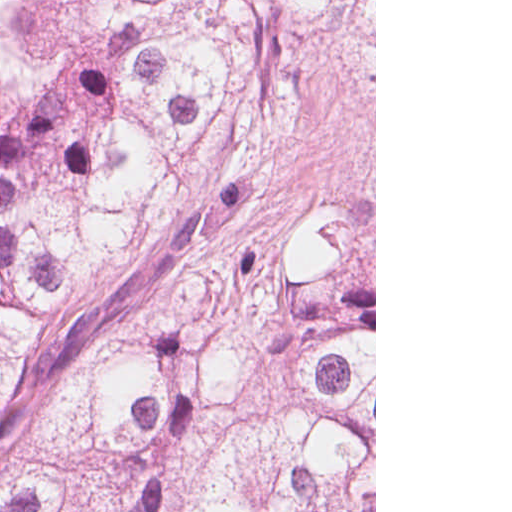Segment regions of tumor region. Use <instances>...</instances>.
<instances>
[{
	"label": "tumor region",
	"instance_id": "e687c5a6",
	"mask_svg": "<svg viewBox=\"0 0 512 512\" xmlns=\"http://www.w3.org/2000/svg\"><path fill=\"white\" fill-rule=\"evenodd\" d=\"M281 0H0V512H115Z\"/></svg>",
	"mask_w": 512,
	"mask_h": 512
}]
</instances>
